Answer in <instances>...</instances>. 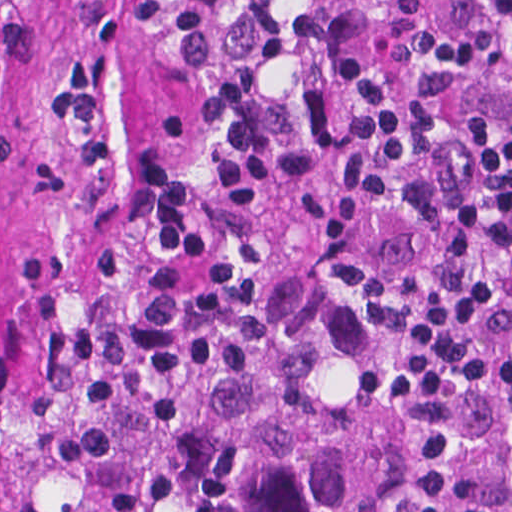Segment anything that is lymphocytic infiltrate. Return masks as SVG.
<instances>
[{
	"label": "lymphocytic infiltrate",
	"mask_w": 512,
	"mask_h": 512,
	"mask_svg": "<svg viewBox=\"0 0 512 512\" xmlns=\"http://www.w3.org/2000/svg\"><path fill=\"white\" fill-rule=\"evenodd\" d=\"M306 237L373 322L364 384L512 425V0L372 40Z\"/></svg>",
	"instance_id": "f902f5d3"
}]
</instances>
